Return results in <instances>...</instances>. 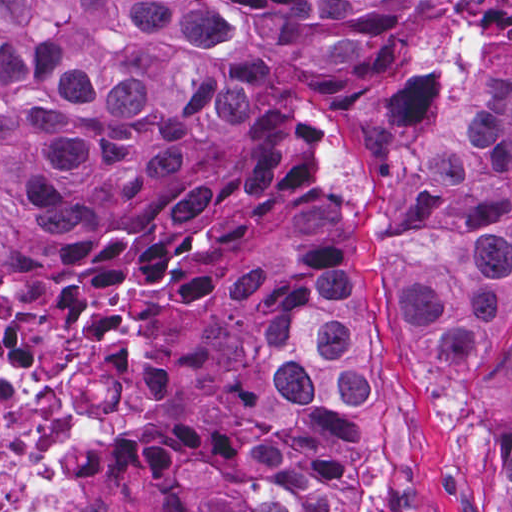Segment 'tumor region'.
<instances>
[{"label": "tumor region", "mask_w": 512, "mask_h": 512, "mask_svg": "<svg viewBox=\"0 0 512 512\" xmlns=\"http://www.w3.org/2000/svg\"><path fill=\"white\" fill-rule=\"evenodd\" d=\"M380 1L0 0V270L19 224L85 241L80 197L176 179L180 106L202 101L237 124L269 73L357 57ZM418 15L414 0L382 68L279 110L255 161L133 233L59 299L110 283L163 322L248 307L264 291L248 249L313 185L321 135L403 62ZM428 214L440 228L399 264L408 345L459 408L473 512H512V65L431 154ZM374 318L368 284L301 273L285 287L266 376L279 413L301 422L292 443L233 469L245 512H335L329 481L360 454L362 408L378 396Z\"/></svg>", "instance_id": "tumor-region-1"}]
</instances>
